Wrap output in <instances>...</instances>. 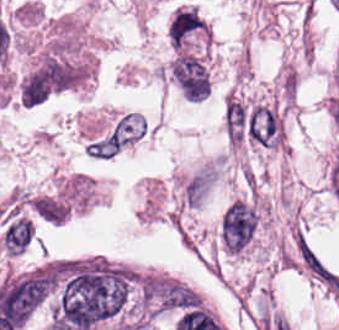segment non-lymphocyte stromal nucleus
<instances>
[{
    "label": "non-lymphocyte stromal nucleus",
    "instance_id": "non-lymphocyte-stromal-nucleus-1",
    "mask_svg": "<svg viewBox=\"0 0 339 330\" xmlns=\"http://www.w3.org/2000/svg\"><path fill=\"white\" fill-rule=\"evenodd\" d=\"M279 120L267 104H254L247 111L246 135L253 141L274 146L278 137Z\"/></svg>",
    "mask_w": 339,
    "mask_h": 330
}]
</instances>
